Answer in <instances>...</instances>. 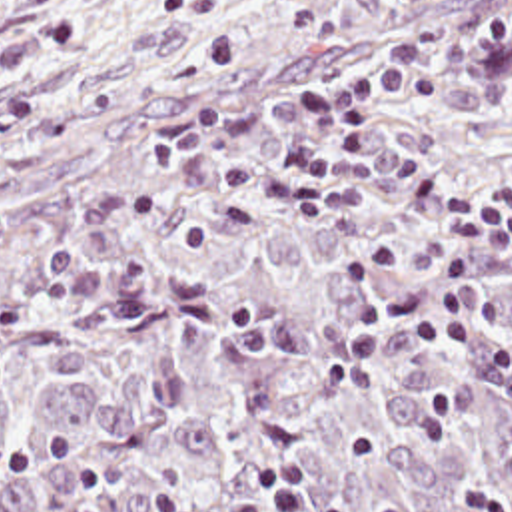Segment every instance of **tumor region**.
I'll return each mask as SVG.
<instances>
[{"instance_id":"obj_1","label":"tumor region","mask_w":512,"mask_h":512,"mask_svg":"<svg viewBox=\"0 0 512 512\" xmlns=\"http://www.w3.org/2000/svg\"><path fill=\"white\" fill-rule=\"evenodd\" d=\"M512 17V0H234L212 35L0 69V512H158L154 482L200 504L244 474L290 466L328 512H456L458 476L500 474L512 398L448 349L458 394L446 440L418 438L410 341L376 345L378 382L326 386L316 368L354 317L340 263L396 239L384 285L436 275L438 227L384 187L356 213L308 221L266 193L260 223L184 255L206 191V151L150 137L208 95L232 123L264 119L252 153L310 95L442 29ZM446 99H352L350 117L436 183L512 215V47H476L436 77ZM482 299L512 337V265L484 257Z\"/></svg>"}]
</instances>
